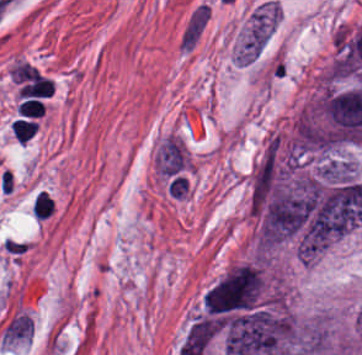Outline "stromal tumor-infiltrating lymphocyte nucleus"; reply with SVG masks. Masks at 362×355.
<instances>
[{"instance_id": "stromal-tumor-infiltrating-lymphocyte-nucleus-1", "label": "stromal tumor-infiltrating lymphocyte nucleus", "mask_w": 362, "mask_h": 355, "mask_svg": "<svg viewBox=\"0 0 362 355\" xmlns=\"http://www.w3.org/2000/svg\"><path fill=\"white\" fill-rule=\"evenodd\" d=\"M10 126L16 141L23 145L34 135L37 127L29 118H15Z\"/></svg>"}, {"instance_id": "stromal-tumor-infiltrating-lymphocyte-nucleus-2", "label": "stromal tumor-infiltrating lymphocyte nucleus", "mask_w": 362, "mask_h": 355, "mask_svg": "<svg viewBox=\"0 0 362 355\" xmlns=\"http://www.w3.org/2000/svg\"><path fill=\"white\" fill-rule=\"evenodd\" d=\"M31 209L35 219L41 220L55 211V204L48 195L41 191L35 195Z\"/></svg>"}]
</instances>
